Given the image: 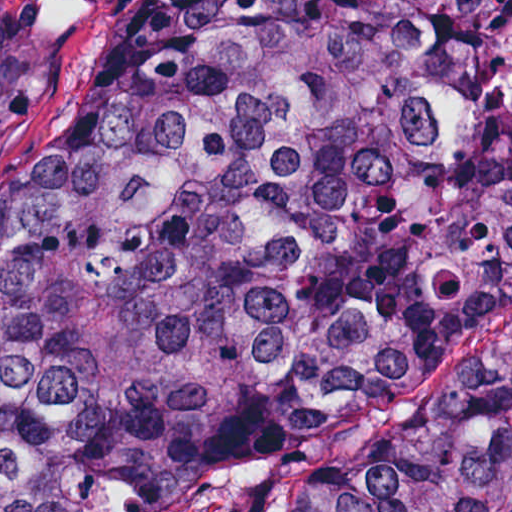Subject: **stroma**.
<instances>
[{"label":"stroma","instance_id":"35a3bbf8","mask_svg":"<svg viewBox=\"0 0 512 512\" xmlns=\"http://www.w3.org/2000/svg\"><path fill=\"white\" fill-rule=\"evenodd\" d=\"M130 0H0V169L51 114L90 87ZM512 339V300L452 327L381 406L278 447L207 485L175 512H271L284 481L328 456L375 448L454 379Z\"/></svg>","mask_w":512,"mask_h":512}]
</instances>
